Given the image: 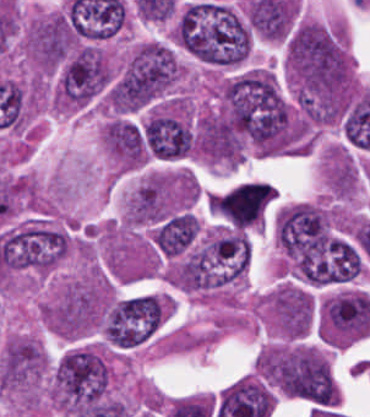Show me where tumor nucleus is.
Segmentation results:
<instances>
[{
  "mask_svg": "<svg viewBox=\"0 0 370 417\" xmlns=\"http://www.w3.org/2000/svg\"><path fill=\"white\" fill-rule=\"evenodd\" d=\"M358 172L350 157L332 155L326 177L328 187L335 197L348 198L355 191Z\"/></svg>",
  "mask_w": 370,
  "mask_h": 417,
  "instance_id": "2083b535",
  "label": "tumor nucleus"
},
{
  "mask_svg": "<svg viewBox=\"0 0 370 417\" xmlns=\"http://www.w3.org/2000/svg\"><path fill=\"white\" fill-rule=\"evenodd\" d=\"M165 314L162 298L143 293L118 298L101 314L100 331L106 344L130 348L149 339Z\"/></svg>",
  "mask_w": 370,
  "mask_h": 417,
  "instance_id": "3d1891a8",
  "label": "tumor nucleus"
},
{
  "mask_svg": "<svg viewBox=\"0 0 370 417\" xmlns=\"http://www.w3.org/2000/svg\"><path fill=\"white\" fill-rule=\"evenodd\" d=\"M174 35L198 61L234 67L250 50L251 33L241 12L227 3L188 2L176 20Z\"/></svg>",
  "mask_w": 370,
  "mask_h": 417,
  "instance_id": "2f306a5c",
  "label": "tumor nucleus"
},
{
  "mask_svg": "<svg viewBox=\"0 0 370 417\" xmlns=\"http://www.w3.org/2000/svg\"><path fill=\"white\" fill-rule=\"evenodd\" d=\"M180 78L181 67L170 47L147 40L127 56L112 82V107L142 109L165 96Z\"/></svg>",
  "mask_w": 370,
  "mask_h": 417,
  "instance_id": "8643909e",
  "label": "tumor nucleus"
},
{
  "mask_svg": "<svg viewBox=\"0 0 370 417\" xmlns=\"http://www.w3.org/2000/svg\"><path fill=\"white\" fill-rule=\"evenodd\" d=\"M268 379L284 395L336 404L337 393L320 352L309 347L273 348L268 356Z\"/></svg>",
  "mask_w": 370,
  "mask_h": 417,
  "instance_id": "2cbd58db",
  "label": "tumor nucleus"
},
{
  "mask_svg": "<svg viewBox=\"0 0 370 417\" xmlns=\"http://www.w3.org/2000/svg\"><path fill=\"white\" fill-rule=\"evenodd\" d=\"M110 379L111 369L100 349H68L52 374V401L64 417L74 416L107 398Z\"/></svg>",
  "mask_w": 370,
  "mask_h": 417,
  "instance_id": "5ab6c2c4",
  "label": "tumor nucleus"
}]
</instances>
